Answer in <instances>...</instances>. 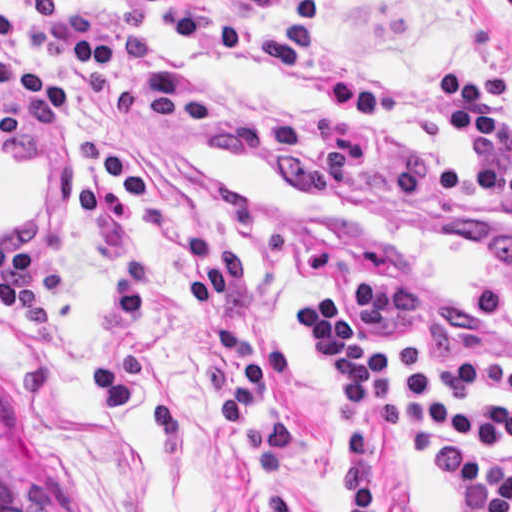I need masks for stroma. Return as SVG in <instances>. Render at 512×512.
<instances>
[{"mask_svg":"<svg viewBox=\"0 0 512 512\" xmlns=\"http://www.w3.org/2000/svg\"><path fill=\"white\" fill-rule=\"evenodd\" d=\"M204 15L210 0H184ZM321 55L405 96L452 92L444 69L512 79V0H324ZM11 36L0 59L16 74L0 106L24 101L30 74L71 98L68 115L29 110L23 141L0 147V468L41 512H258L228 432L223 393L200 362V337L182 274L164 239L135 212L128 243L155 306L137 342L138 401L119 414L95 405L92 371L109 300V248L82 216L81 142L103 108L87 106L81 69L51 51L57 24L89 14L155 42L171 63L228 101L289 108L322 122L304 79L233 63L177 41L149 16L100 0H56L29 22L0 0ZM510 133L512 123H504ZM374 166L335 197H304L284 176L209 144L197 123L117 119L143 186L184 230L238 249L246 305L225 319L256 339L289 344L294 374L279 389L298 426L296 512H329L337 433L325 362L295 312L318 288L343 309L365 345L427 351L440 392L476 408L512 404L509 315L473 317L494 228L512 229V204L462 190H415L392 203L386 171L399 156H433L459 169L465 153L423 118L362 125ZM512 464V452L490 453ZM377 512H455L420 448L372 437Z\"/></svg>","mask_w":512,"mask_h":512,"instance_id":"stroma-1","label":"stroma"}]
</instances>
